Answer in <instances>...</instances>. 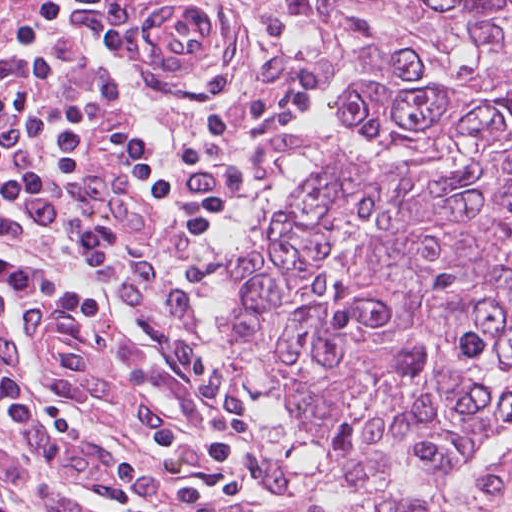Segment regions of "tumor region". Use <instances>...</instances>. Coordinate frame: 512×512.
<instances>
[{
	"mask_svg": "<svg viewBox=\"0 0 512 512\" xmlns=\"http://www.w3.org/2000/svg\"><path fill=\"white\" fill-rule=\"evenodd\" d=\"M349 125L233 260L266 512H512V0H281Z\"/></svg>",
	"mask_w": 512,
	"mask_h": 512,
	"instance_id": "obj_1",
	"label": "tumor region"
}]
</instances>
